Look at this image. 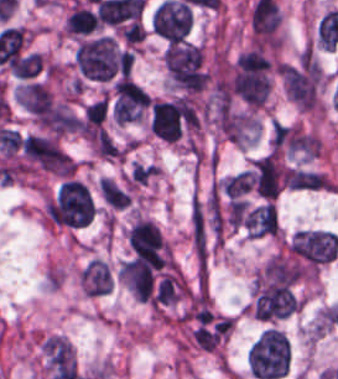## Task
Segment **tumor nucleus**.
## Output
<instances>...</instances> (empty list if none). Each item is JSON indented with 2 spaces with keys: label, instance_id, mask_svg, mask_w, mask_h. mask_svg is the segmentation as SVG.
<instances>
[{
  "label": "tumor nucleus",
  "instance_id": "obj_9",
  "mask_svg": "<svg viewBox=\"0 0 338 379\" xmlns=\"http://www.w3.org/2000/svg\"><path fill=\"white\" fill-rule=\"evenodd\" d=\"M78 282L85 295L101 297L109 292L111 285V270L101 259L90 258L80 269Z\"/></svg>",
  "mask_w": 338,
  "mask_h": 379
},
{
  "label": "tumor nucleus",
  "instance_id": "obj_14",
  "mask_svg": "<svg viewBox=\"0 0 338 379\" xmlns=\"http://www.w3.org/2000/svg\"><path fill=\"white\" fill-rule=\"evenodd\" d=\"M106 111L105 95L84 105L83 119L87 124L100 126L104 121Z\"/></svg>",
  "mask_w": 338,
  "mask_h": 379
},
{
  "label": "tumor nucleus",
  "instance_id": "obj_13",
  "mask_svg": "<svg viewBox=\"0 0 338 379\" xmlns=\"http://www.w3.org/2000/svg\"><path fill=\"white\" fill-rule=\"evenodd\" d=\"M158 167L156 164L134 162L127 177L128 188H140L153 182Z\"/></svg>",
  "mask_w": 338,
  "mask_h": 379
},
{
  "label": "tumor nucleus",
  "instance_id": "obj_3",
  "mask_svg": "<svg viewBox=\"0 0 338 379\" xmlns=\"http://www.w3.org/2000/svg\"><path fill=\"white\" fill-rule=\"evenodd\" d=\"M120 59L121 54L108 35L81 41L74 53V63L81 76L97 81L113 78L119 72Z\"/></svg>",
  "mask_w": 338,
  "mask_h": 379
},
{
  "label": "tumor nucleus",
  "instance_id": "obj_10",
  "mask_svg": "<svg viewBox=\"0 0 338 379\" xmlns=\"http://www.w3.org/2000/svg\"><path fill=\"white\" fill-rule=\"evenodd\" d=\"M288 190L294 191H333L331 178L320 170L289 167L286 169Z\"/></svg>",
  "mask_w": 338,
  "mask_h": 379
},
{
  "label": "tumor nucleus",
  "instance_id": "obj_2",
  "mask_svg": "<svg viewBox=\"0 0 338 379\" xmlns=\"http://www.w3.org/2000/svg\"><path fill=\"white\" fill-rule=\"evenodd\" d=\"M94 213L87 189L74 179L64 181L48 203V219L53 225L83 227Z\"/></svg>",
  "mask_w": 338,
  "mask_h": 379
},
{
  "label": "tumor nucleus",
  "instance_id": "obj_12",
  "mask_svg": "<svg viewBox=\"0 0 338 379\" xmlns=\"http://www.w3.org/2000/svg\"><path fill=\"white\" fill-rule=\"evenodd\" d=\"M41 67V53L38 51H31L15 60L10 66V72L15 77L27 80L34 77Z\"/></svg>",
  "mask_w": 338,
  "mask_h": 379
},
{
  "label": "tumor nucleus",
  "instance_id": "obj_5",
  "mask_svg": "<svg viewBox=\"0 0 338 379\" xmlns=\"http://www.w3.org/2000/svg\"><path fill=\"white\" fill-rule=\"evenodd\" d=\"M285 96L300 110L316 104L320 68L313 58L284 63L280 69Z\"/></svg>",
  "mask_w": 338,
  "mask_h": 379
},
{
  "label": "tumor nucleus",
  "instance_id": "obj_1",
  "mask_svg": "<svg viewBox=\"0 0 338 379\" xmlns=\"http://www.w3.org/2000/svg\"><path fill=\"white\" fill-rule=\"evenodd\" d=\"M245 362L254 379H274L284 375L290 363L289 344L280 332L265 327L249 345Z\"/></svg>",
  "mask_w": 338,
  "mask_h": 379
},
{
  "label": "tumor nucleus",
  "instance_id": "obj_11",
  "mask_svg": "<svg viewBox=\"0 0 338 379\" xmlns=\"http://www.w3.org/2000/svg\"><path fill=\"white\" fill-rule=\"evenodd\" d=\"M98 191L103 201L115 209L129 205V195L108 177H100Z\"/></svg>",
  "mask_w": 338,
  "mask_h": 379
},
{
  "label": "tumor nucleus",
  "instance_id": "obj_8",
  "mask_svg": "<svg viewBox=\"0 0 338 379\" xmlns=\"http://www.w3.org/2000/svg\"><path fill=\"white\" fill-rule=\"evenodd\" d=\"M242 231L249 238L277 235L280 223L275 203L269 200L247 205L243 209Z\"/></svg>",
  "mask_w": 338,
  "mask_h": 379
},
{
  "label": "tumor nucleus",
  "instance_id": "obj_4",
  "mask_svg": "<svg viewBox=\"0 0 338 379\" xmlns=\"http://www.w3.org/2000/svg\"><path fill=\"white\" fill-rule=\"evenodd\" d=\"M288 251L313 273L338 257V239L327 230H301L290 236Z\"/></svg>",
  "mask_w": 338,
  "mask_h": 379
},
{
  "label": "tumor nucleus",
  "instance_id": "obj_7",
  "mask_svg": "<svg viewBox=\"0 0 338 379\" xmlns=\"http://www.w3.org/2000/svg\"><path fill=\"white\" fill-rule=\"evenodd\" d=\"M250 179L257 195L268 201L275 197L282 182L279 153L273 149L254 158Z\"/></svg>",
  "mask_w": 338,
  "mask_h": 379
},
{
  "label": "tumor nucleus",
  "instance_id": "obj_6",
  "mask_svg": "<svg viewBox=\"0 0 338 379\" xmlns=\"http://www.w3.org/2000/svg\"><path fill=\"white\" fill-rule=\"evenodd\" d=\"M193 16L187 4L176 1H162L153 11L151 29L161 38L182 42L187 35Z\"/></svg>",
  "mask_w": 338,
  "mask_h": 379
}]
</instances>
